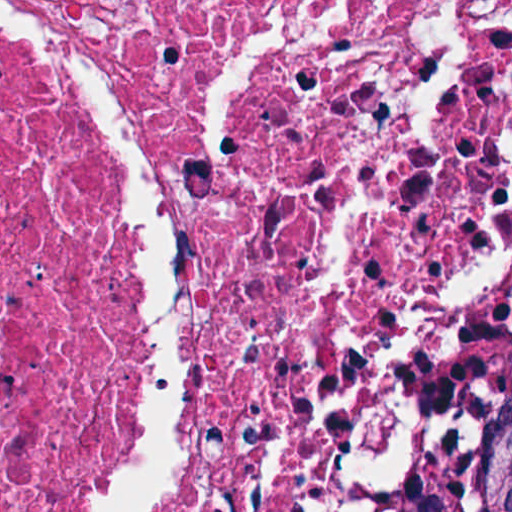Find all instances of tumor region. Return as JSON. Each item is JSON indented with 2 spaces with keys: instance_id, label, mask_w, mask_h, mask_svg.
I'll use <instances>...</instances> for the list:
<instances>
[{
  "instance_id": "e687c5a6",
  "label": "tumor region",
  "mask_w": 512,
  "mask_h": 512,
  "mask_svg": "<svg viewBox=\"0 0 512 512\" xmlns=\"http://www.w3.org/2000/svg\"><path fill=\"white\" fill-rule=\"evenodd\" d=\"M429 512H512V420L455 452Z\"/></svg>"
}]
</instances>
